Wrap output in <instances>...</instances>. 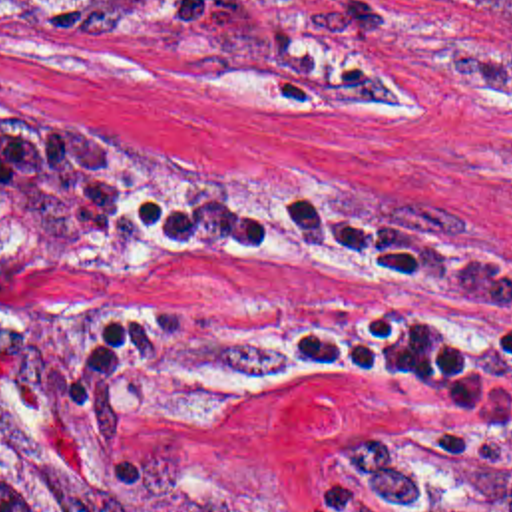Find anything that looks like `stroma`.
<instances>
[{
    "instance_id": "stroma-1",
    "label": "stroma",
    "mask_w": 512,
    "mask_h": 512,
    "mask_svg": "<svg viewBox=\"0 0 512 512\" xmlns=\"http://www.w3.org/2000/svg\"><path fill=\"white\" fill-rule=\"evenodd\" d=\"M97 160L342 188L512 268V0L0 3V411L61 512L137 511L121 451L153 433L260 512H310L328 461L449 397L354 385L254 334L260 304L427 268L121 238L77 196Z\"/></svg>"
}]
</instances>
